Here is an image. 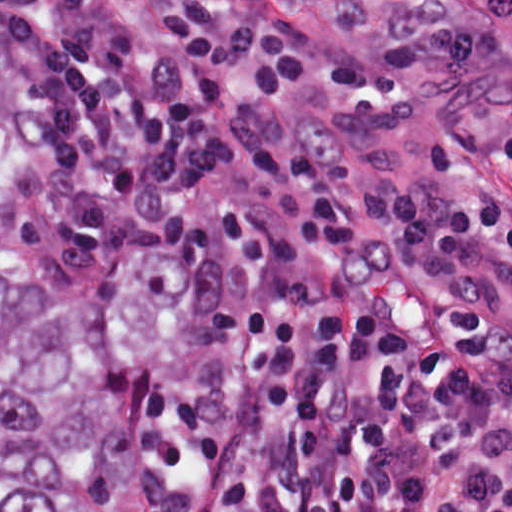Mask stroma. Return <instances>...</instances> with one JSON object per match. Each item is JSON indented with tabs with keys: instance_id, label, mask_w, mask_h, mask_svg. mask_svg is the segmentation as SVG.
<instances>
[{
	"instance_id": "stroma-1",
	"label": "stroma",
	"mask_w": 512,
	"mask_h": 512,
	"mask_svg": "<svg viewBox=\"0 0 512 512\" xmlns=\"http://www.w3.org/2000/svg\"><path fill=\"white\" fill-rule=\"evenodd\" d=\"M88 1L120 23L137 54L161 51L167 40L162 17L190 1H210L233 14L274 17L318 43L337 62H367L436 37L477 38L502 55L512 54V0ZM21 179L2 210V267L16 308L25 318L41 321L58 302L83 289L102 265L33 268L38 214L18 196ZM166 253L185 264L180 249ZM185 320L146 363L127 398L128 440L148 512H164L147 476V422L156 371Z\"/></svg>"
}]
</instances>
